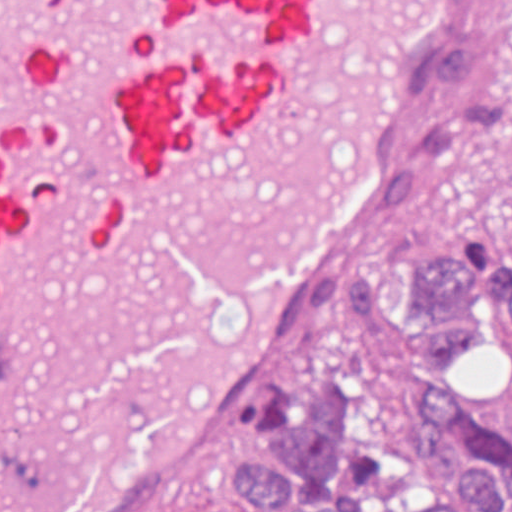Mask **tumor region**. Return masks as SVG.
I'll return each instance as SVG.
<instances>
[{
    "mask_svg": "<svg viewBox=\"0 0 512 512\" xmlns=\"http://www.w3.org/2000/svg\"><path fill=\"white\" fill-rule=\"evenodd\" d=\"M442 90L408 209L431 205L462 163L485 169L512 242V0H473L436 55ZM405 299L474 310L499 286L473 242H415ZM494 336H472L450 391L421 403L410 431H382L344 375L318 360L298 381L277 437L220 448V477L265 512H512V407L489 397ZM172 512H229L205 476L176 493Z\"/></svg>",
    "mask_w": 512,
    "mask_h": 512,
    "instance_id": "tumor-region-1",
    "label": "tumor region"
}]
</instances>
